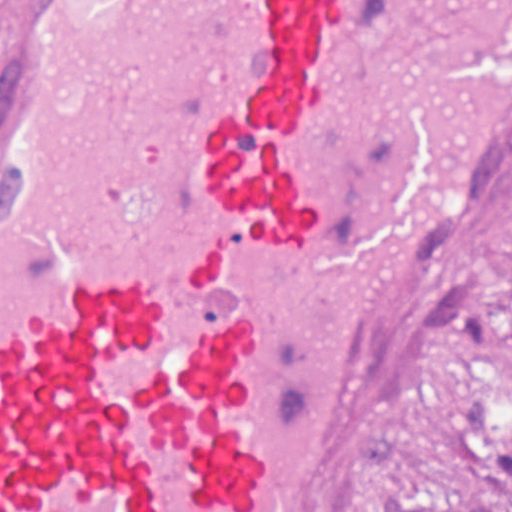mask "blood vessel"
Wrapping results in <instances>:
<instances>
[{"label":"blood vessel","mask_w":512,"mask_h":512,"mask_svg":"<svg viewBox=\"0 0 512 512\" xmlns=\"http://www.w3.org/2000/svg\"><path fill=\"white\" fill-rule=\"evenodd\" d=\"M512 172V0H0V512H318Z\"/></svg>","instance_id":"1"}]
</instances>
